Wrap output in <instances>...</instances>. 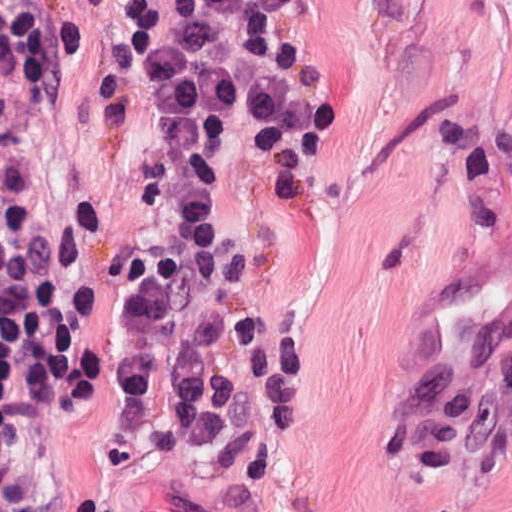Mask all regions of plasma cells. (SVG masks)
Segmentation results:
<instances>
[{
	"instance_id": "1",
	"label": "plasma cells",
	"mask_w": 512,
	"mask_h": 512,
	"mask_svg": "<svg viewBox=\"0 0 512 512\" xmlns=\"http://www.w3.org/2000/svg\"><path fill=\"white\" fill-rule=\"evenodd\" d=\"M473 376L431 368L371 434L378 454L432 469L488 438L512 437V317L472 337Z\"/></svg>"
}]
</instances>
